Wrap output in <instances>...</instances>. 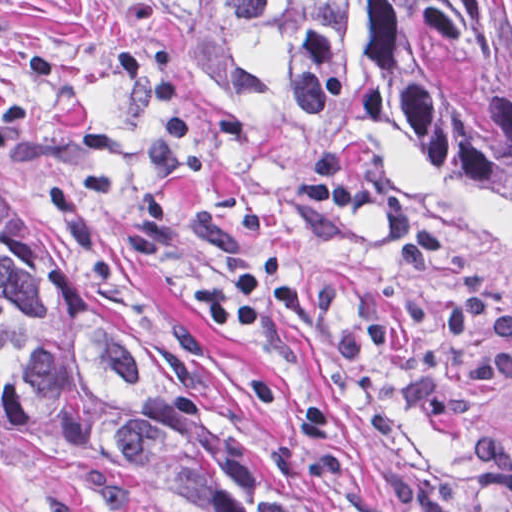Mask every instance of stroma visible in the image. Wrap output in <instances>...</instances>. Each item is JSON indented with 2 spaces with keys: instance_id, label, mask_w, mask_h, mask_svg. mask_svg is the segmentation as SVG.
<instances>
[{
  "instance_id": "stroma-1",
  "label": "stroma",
  "mask_w": 512,
  "mask_h": 512,
  "mask_svg": "<svg viewBox=\"0 0 512 512\" xmlns=\"http://www.w3.org/2000/svg\"><path fill=\"white\" fill-rule=\"evenodd\" d=\"M324 145L512 308V219L454 164L226 79L92 0H0V174L147 297L239 435L322 512H512L480 499L470 463L475 434L512 436V384L464 378L489 336L449 333L457 277L409 271L373 211L292 194ZM268 252L311 310L214 329L205 296ZM0 512L206 511L0 419Z\"/></svg>"
}]
</instances>
